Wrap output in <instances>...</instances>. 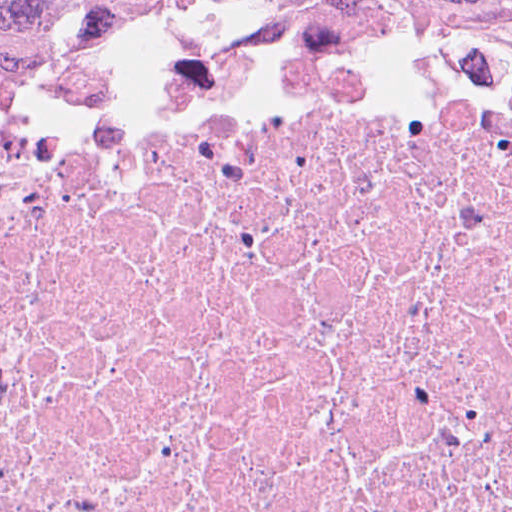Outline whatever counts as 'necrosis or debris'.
I'll return each instance as SVG.
<instances>
[{
	"instance_id": "1",
	"label": "necrosis or debris",
	"mask_w": 512,
	"mask_h": 512,
	"mask_svg": "<svg viewBox=\"0 0 512 512\" xmlns=\"http://www.w3.org/2000/svg\"><path fill=\"white\" fill-rule=\"evenodd\" d=\"M0 512H512V88L189 65L1 131Z\"/></svg>"
}]
</instances>
